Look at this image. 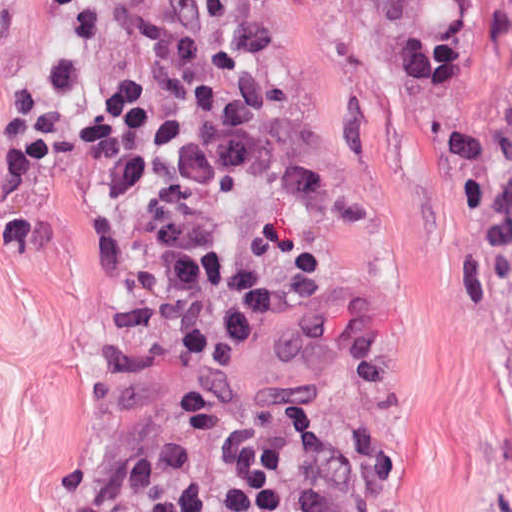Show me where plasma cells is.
<instances>
[{
  "instance_id": "plasma-cells-1",
  "label": "plasma cells",
  "mask_w": 512,
  "mask_h": 512,
  "mask_svg": "<svg viewBox=\"0 0 512 512\" xmlns=\"http://www.w3.org/2000/svg\"><path fill=\"white\" fill-rule=\"evenodd\" d=\"M9 190L33 185L67 134V101L48 84L17 82L8 113ZM367 202L307 160L278 155L260 170L254 208L228 250L198 231L181 194L131 190L106 208L100 240L164 320L142 341L102 336L95 361L119 391L168 386L198 451L232 442L238 418L221 373L255 332H278L316 353L349 394L381 404L398 386L386 340L360 312L318 294L316 219L365 227Z\"/></svg>"
}]
</instances>
